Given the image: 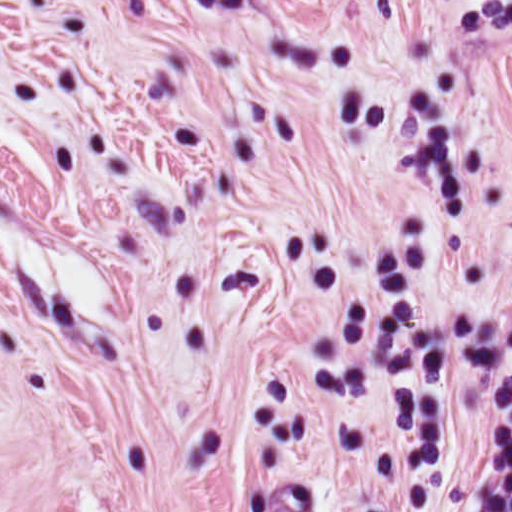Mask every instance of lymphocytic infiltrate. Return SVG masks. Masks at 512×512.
<instances>
[{
	"mask_svg": "<svg viewBox=\"0 0 512 512\" xmlns=\"http://www.w3.org/2000/svg\"><path fill=\"white\" fill-rule=\"evenodd\" d=\"M439 512H512V338L470 422Z\"/></svg>",
	"mask_w": 512,
	"mask_h": 512,
	"instance_id": "lymphocytic-infiltrate-1",
	"label": "lymphocytic infiltrate"
}]
</instances>
